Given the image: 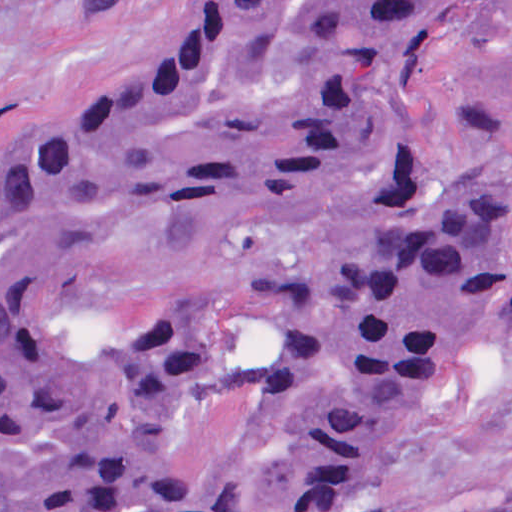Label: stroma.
Instances as JSON below:
<instances>
[{
	"label": "stroma",
	"mask_w": 512,
	"mask_h": 512,
	"mask_svg": "<svg viewBox=\"0 0 512 512\" xmlns=\"http://www.w3.org/2000/svg\"><path fill=\"white\" fill-rule=\"evenodd\" d=\"M207 0H0V154L142 70ZM407 128L421 171H512V0H483L417 72ZM336 512H512V346L415 405Z\"/></svg>",
	"instance_id": "stroma-1"
}]
</instances>
